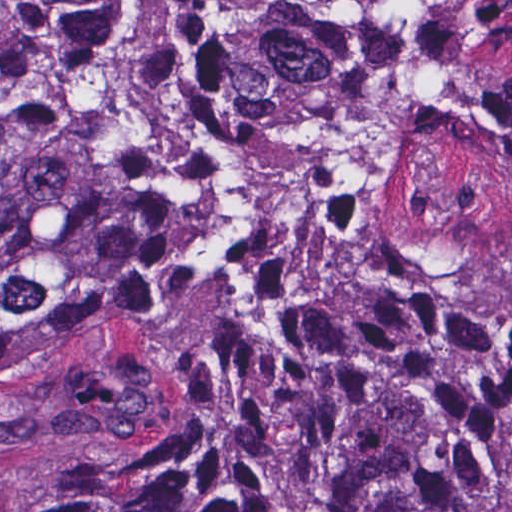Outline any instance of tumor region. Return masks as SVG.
I'll list each match as a JSON object with an SVG mask.
<instances>
[{"mask_svg":"<svg viewBox=\"0 0 512 512\" xmlns=\"http://www.w3.org/2000/svg\"><path fill=\"white\" fill-rule=\"evenodd\" d=\"M2 1L0 379L198 427L39 512H512V0Z\"/></svg>","mask_w":512,"mask_h":512,"instance_id":"e687c5a6","label":"tumor region"}]
</instances>
